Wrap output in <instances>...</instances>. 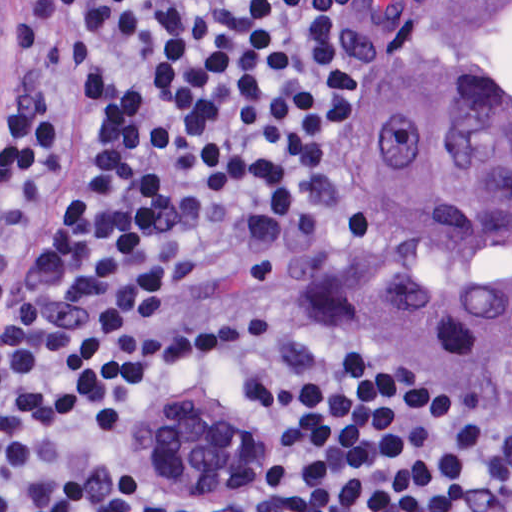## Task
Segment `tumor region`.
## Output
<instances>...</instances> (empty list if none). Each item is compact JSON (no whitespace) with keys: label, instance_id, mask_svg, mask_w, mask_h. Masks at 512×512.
<instances>
[{"label":"tumor region","instance_id":"e687c5a6","mask_svg":"<svg viewBox=\"0 0 512 512\" xmlns=\"http://www.w3.org/2000/svg\"><path fill=\"white\" fill-rule=\"evenodd\" d=\"M377 46L397 80L363 121L380 185L363 351L512 429V1H395ZM129 428L140 476L189 497L282 481L274 439L198 386Z\"/></svg>","mask_w":512,"mask_h":512}]
</instances>
